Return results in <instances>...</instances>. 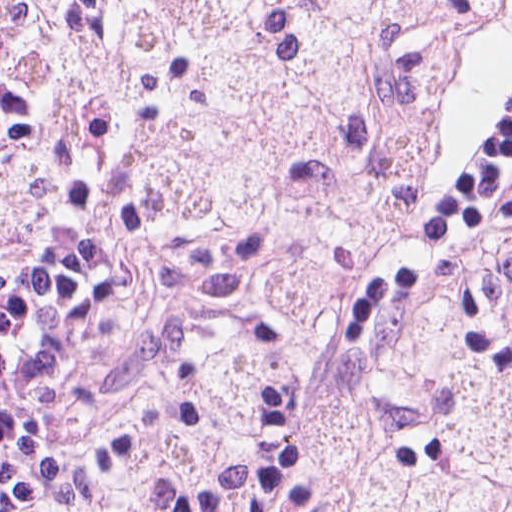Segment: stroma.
<instances>
[{
	"label": "stroma",
	"mask_w": 512,
	"mask_h": 512,
	"mask_svg": "<svg viewBox=\"0 0 512 512\" xmlns=\"http://www.w3.org/2000/svg\"><path fill=\"white\" fill-rule=\"evenodd\" d=\"M25 1L37 44V111L59 132L74 179L100 204L128 252L110 270L99 314L61 377L33 469L63 512H327L324 497L284 487L248 505H175L106 487L99 445L153 371L212 300L200 262L155 249L122 171L85 149L72 112L69 1H492L446 65L410 234L356 299L345 333L404 323L445 279L469 268L512 209V0H0Z\"/></svg>",
	"instance_id": "35a3bbf8"
}]
</instances>
